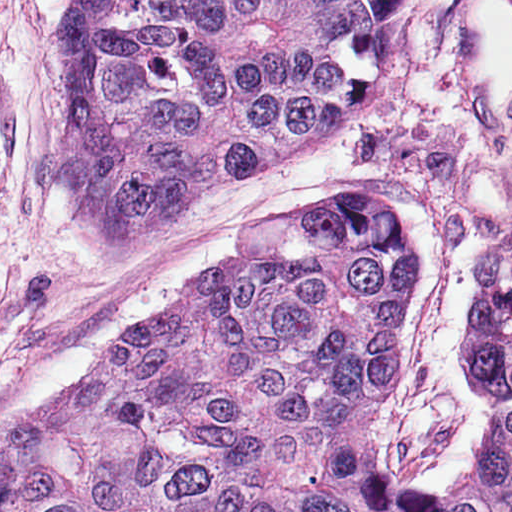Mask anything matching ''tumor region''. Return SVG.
<instances>
[{"label": "tumor region", "instance_id": "obj_1", "mask_svg": "<svg viewBox=\"0 0 512 512\" xmlns=\"http://www.w3.org/2000/svg\"><path fill=\"white\" fill-rule=\"evenodd\" d=\"M58 178L152 239L219 187L301 161L358 97L314 0H72ZM420 286L388 200L261 213L84 379L0 429V512H512L497 410L476 471L408 491L374 426Z\"/></svg>", "mask_w": 512, "mask_h": 512}]
</instances>
